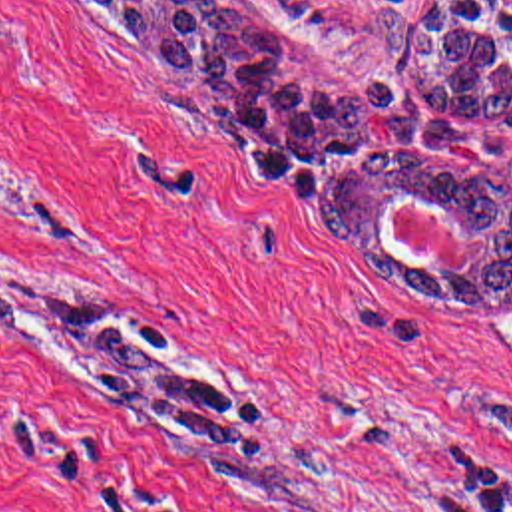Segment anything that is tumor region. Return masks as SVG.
<instances>
[{
    "label": "tumor region",
    "mask_w": 512,
    "mask_h": 512,
    "mask_svg": "<svg viewBox=\"0 0 512 512\" xmlns=\"http://www.w3.org/2000/svg\"><path fill=\"white\" fill-rule=\"evenodd\" d=\"M133 27L166 87L198 111L256 174L298 190L308 218L397 292L429 302L512 298V0H433L407 31L380 13L399 47L389 87L332 97L272 63L268 37L224 0H89ZM407 196L449 210L481 240L463 268H419L385 224ZM0 336L41 350H81L107 374L93 395L156 437L230 453L256 425V403L164 354L111 308H81L25 276L0 278Z\"/></svg>",
    "instance_id": "tumor-region-1"
}]
</instances>
